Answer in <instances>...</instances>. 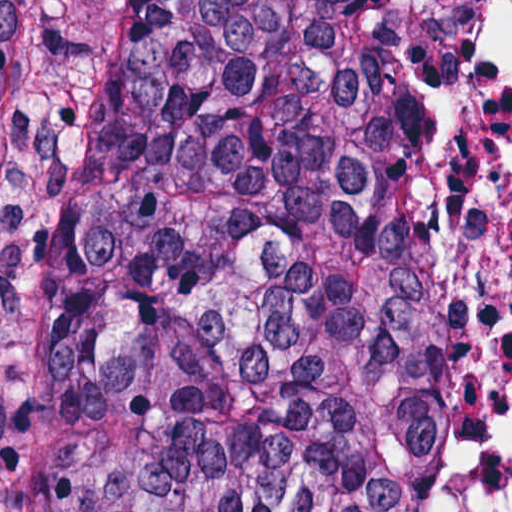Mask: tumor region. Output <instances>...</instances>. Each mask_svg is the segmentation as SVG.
<instances>
[{
    "label": "tumor region",
    "mask_w": 512,
    "mask_h": 512,
    "mask_svg": "<svg viewBox=\"0 0 512 512\" xmlns=\"http://www.w3.org/2000/svg\"><path fill=\"white\" fill-rule=\"evenodd\" d=\"M475 340L435 0H0V512H435Z\"/></svg>",
    "instance_id": "1"
}]
</instances>
